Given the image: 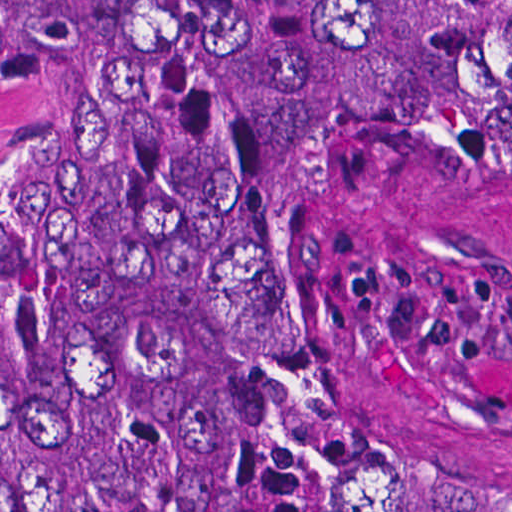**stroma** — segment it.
Masks as SVG:
<instances>
[{
	"label": "stroma",
	"instance_id": "obj_1",
	"mask_svg": "<svg viewBox=\"0 0 512 512\" xmlns=\"http://www.w3.org/2000/svg\"><path fill=\"white\" fill-rule=\"evenodd\" d=\"M319 355L512 466V146L396 154L318 258Z\"/></svg>",
	"mask_w": 512,
	"mask_h": 512
}]
</instances>
